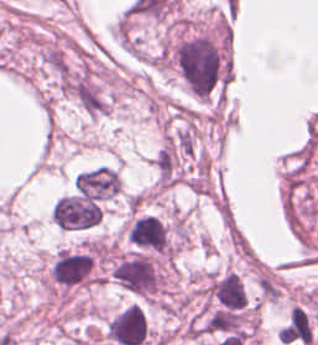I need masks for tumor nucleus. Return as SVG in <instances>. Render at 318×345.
Returning <instances> with one entry per match:
<instances>
[{"label":"tumor nucleus","mask_w":318,"mask_h":345,"mask_svg":"<svg viewBox=\"0 0 318 345\" xmlns=\"http://www.w3.org/2000/svg\"><path fill=\"white\" fill-rule=\"evenodd\" d=\"M73 190L90 200L112 201L120 194L118 170L97 165L80 170L72 179Z\"/></svg>","instance_id":"2f306a5c"}]
</instances>
